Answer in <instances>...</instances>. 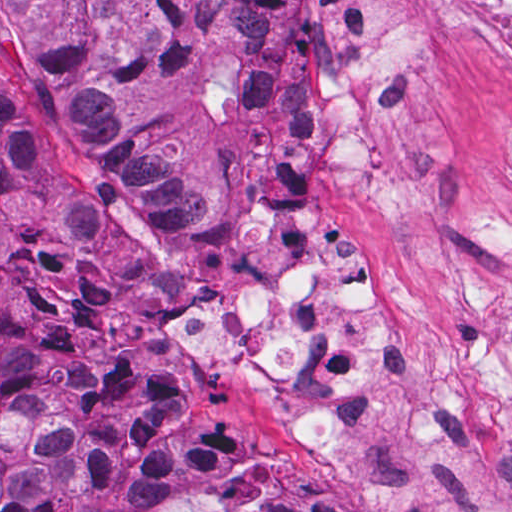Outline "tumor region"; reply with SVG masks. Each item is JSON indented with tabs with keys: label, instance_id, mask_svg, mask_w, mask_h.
<instances>
[{
	"label": "tumor region",
	"instance_id": "tumor-region-1",
	"mask_svg": "<svg viewBox=\"0 0 512 512\" xmlns=\"http://www.w3.org/2000/svg\"><path fill=\"white\" fill-rule=\"evenodd\" d=\"M288 0H2L0 41L34 103L114 191L161 224L217 221L225 184L282 139ZM22 120L0 112V204L26 175ZM0 262L46 339L54 389L103 445L87 485L184 479L228 452L233 427L162 373L104 233H30ZM86 432L27 386L0 326V512H109L77 499ZM113 512H220L131 483ZM244 512H259V507ZM267 512H349L299 478Z\"/></svg>",
	"mask_w": 512,
	"mask_h": 512
}]
</instances>
